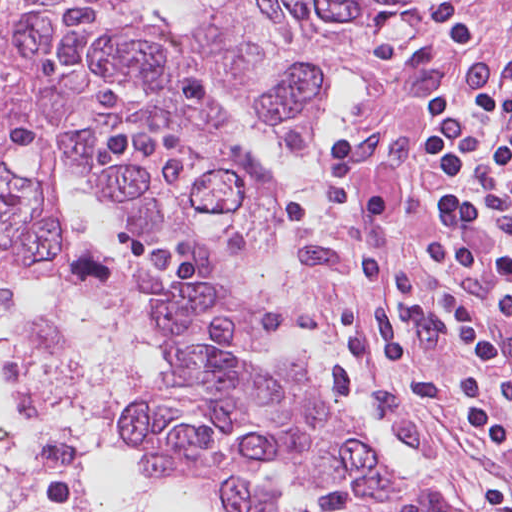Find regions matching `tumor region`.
Here are the masks:
<instances>
[{"label":"tumor region","instance_id":"1","mask_svg":"<svg viewBox=\"0 0 512 512\" xmlns=\"http://www.w3.org/2000/svg\"><path fill=\"white\" fill-rule=\"evenodd\" d=\"M409 0H32L0 93V253L66 251L73 178L94 180L179 348L133 393L140 477L210 512H403L405 476L294 359L221 344L259 322L204 258L243 183L221 152L327 87Z\"/></svg>","mask_w":512,"mask_h":512}]
</instances>
